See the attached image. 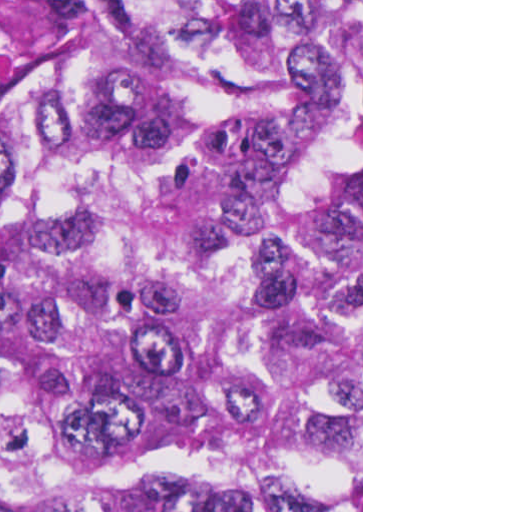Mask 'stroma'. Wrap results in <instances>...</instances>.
<instances>
[{
	"instance_id": "stroma-1",
	"label": "stroma",
	"mask_w": 512,
	"mask_h": 512,
	"mask_svg": "<svg viewBox=\"0 0 512 512\" xmlns=\"http://www.w3.org/2000/svg\"><path fill=\"white\" fill-rule=\"evenodd\" d=\"M77 0H0V93H23L74 59ZM338 512H363V0H361V485Z\"/></svg>"
}]
</instances>
